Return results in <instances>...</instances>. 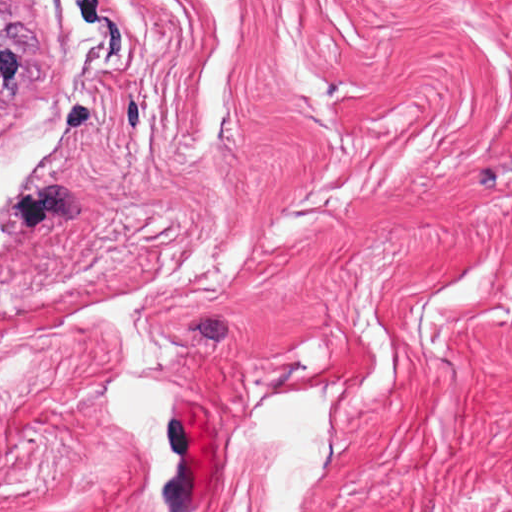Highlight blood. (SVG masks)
I'll use <instances>...</instances> for the list:
<instances>
[{"label":"blood","instance_id":"1a1defca","mask_svg":"<svg viewBox=\"0 0 512 512\" xmlns=\"http://www.w3.org/2000/svg\"><path fill=\"white\" fill-rule=\"evenodd\" d=\"M183 470L213 472L214 430L210 408L190 399L173 398Z\"/></svg>","mask_w":512,"mask_h":512}]
</instances>
